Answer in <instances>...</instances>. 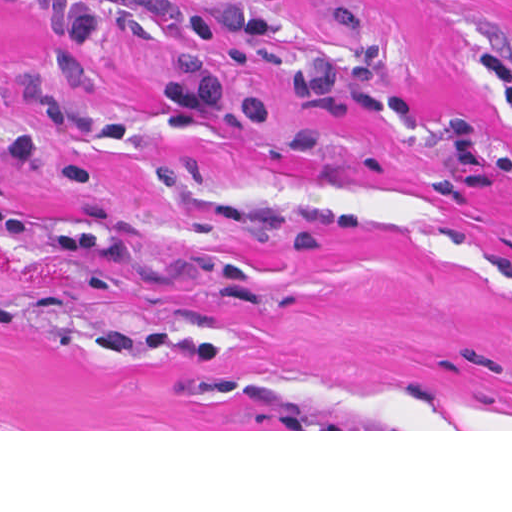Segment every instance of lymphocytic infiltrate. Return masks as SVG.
<instances>
[{"instance_id":"1","label":"lymphocytic infiltrate","mask_w":512,"mask_h":512,"mask_svg":"<svg viewBox=\"0 0 512 512\" xmlns=\"http://www.w3.org/2000/svg\"><path fill=\"white\" fill-rule=\"evenodd\" d=\"M284 0H256L225 16H210L174 0H72L70 22L59 42L61 69L82 76L104 26L140 25L166 42L176 60L170 97L188 115H207L227 85L218 66V45L228 35L248 40L277 37Z\"/></svg>"}]
</instances>
